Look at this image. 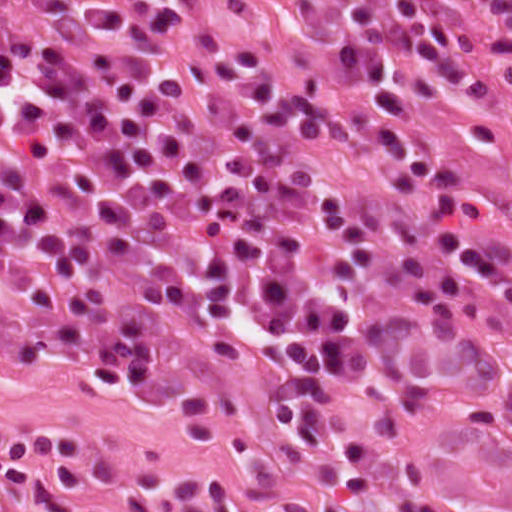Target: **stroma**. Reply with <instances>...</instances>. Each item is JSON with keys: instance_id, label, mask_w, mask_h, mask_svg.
Returning <instances> with one entry per match:
<instances>
[{"instance_id": "1", "label": "stroma", "mask_w": 512, "mask_h": 512, "mask_svg": "<svg viewBox=\"0 0 512 512\" xmlns=\"http://www.w3.org/2000/svg\"><path fill=\"white\" fill-rule=\"evenodd\" d=\"M357 0H199L235 39L258 48L322 95L348 120L365 154L390 183L380 125L422 151L452 159L486 205L488 218L453 223L485 239V270L512 277V84L497 74L483 25L462 20L472 62L419 115L365 103L348 58ZM407 205L428 241L431 205L422 190ZM475 271L467 268L464 282ZM184 356L217 378L228 397L212 420H180L166 407L119 392L72 361L0 357V434L66 436L90 443L116 506L84 512H397L391 457L366 462L354 492L333 435L308 450L270 403L292 380L285 360L262 347H210L170 328ZM364 442L380 415L395 421L427 474L430 495L452 512H512V413L474 355L464 295L429 356L402 380L366 391H327ZM82 437V438H81Z\"/></svg>"}]
</instances>
